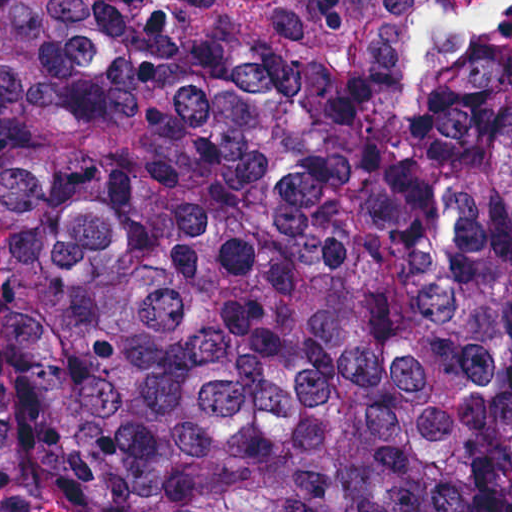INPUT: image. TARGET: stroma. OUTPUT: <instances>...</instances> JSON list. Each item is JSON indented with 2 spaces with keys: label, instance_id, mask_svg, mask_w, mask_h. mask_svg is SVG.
<instances>
[{
  "label": "stroma",
  "instance_id": "stroma-1",
  "mask_svg": "<svg viewBox=\"0 0 512 512\" xmlns=\"http://www.w3.org/2000/svg\"><path fill=\"white\" fill-rule=\"evenodd\" d=\"M0 512H147L112 484H58Z\"/></svg>",
  "mask_w": 512,
  "mask_h": 512
}]
</instances>
